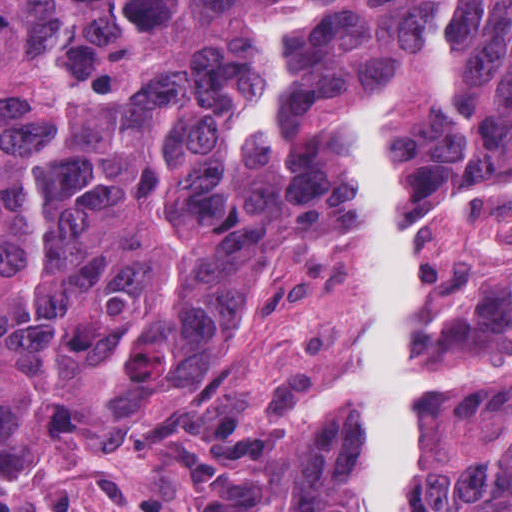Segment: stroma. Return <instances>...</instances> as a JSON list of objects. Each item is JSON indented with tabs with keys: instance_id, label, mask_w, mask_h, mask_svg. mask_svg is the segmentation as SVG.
I'll use <instances>...</instances> for the list:
<instances>
[{
	"instance_id": "1",
	"label": "stroma",
	"mask_w": 512,
	"mask_h": 512,
	"mask_svg": "<svg viewBox=\"0 0 512 512\" xmlns=\"http://www.w3.org/2000/svg\"><path fill=\"white\" fill-rule=\"evenodd\" d=\"M400 206L427 224L420 335L430 369L482 351L508 362L512 169H459ZM504 371L425 383L426 431L395 512L426 511L457 420ZM363 373L356 232L274 258L125 429L0 428V512H365V410L306 420Z\"/></svg>"
}]
</instances>
